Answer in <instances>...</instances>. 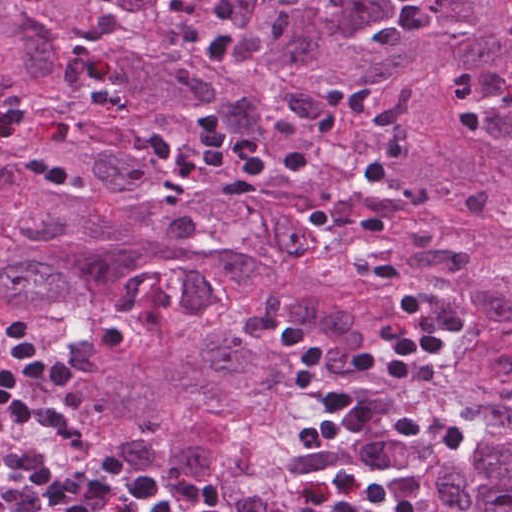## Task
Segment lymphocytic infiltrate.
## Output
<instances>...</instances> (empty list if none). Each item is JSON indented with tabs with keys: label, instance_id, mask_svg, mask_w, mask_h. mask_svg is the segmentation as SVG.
Segmentation results:
<instances>
[{
	"label": "lymphocytic infiltrate",
	"instance_id": "obj_1",
	"mask_svg": "<svg viewBox=\"0 0 512 512\" xmlns=\"http://www.w3.org/2000/svg\"><path fill=\"white\" fill-rule=\"evenodd\" d=\"M500 101L512 109V62ZM197 133L177 148L159 125L150 123L147 140L152 151L165 163L192 181L210 165L229 172L220 183L223 199H248L266 178L278 173L302 177L307 173V156L294 151L283 156L253 153L247 138L227 129L217 113L201 111L195 120ZM359 246L385 300L403 314L406 327L398 337L382 347L381 355L368 353L358 359V369L366 375L390 378L408 386L419 359H436L448 354L458 339L456 329L431 321L419 297L400 279L399 265L386 227L376 216L359 231ZM275 340L294 359L295 388L311 405L335 422L343 431L365 440L402 439L423 442L437 451H459L465 433L427 416L403 417L384 412L354 395L329 384L316 346L293 322L283 320Z\"/></svg>",
	"mask_w": 512,
	"mask_h": 512
}]
</instances>
